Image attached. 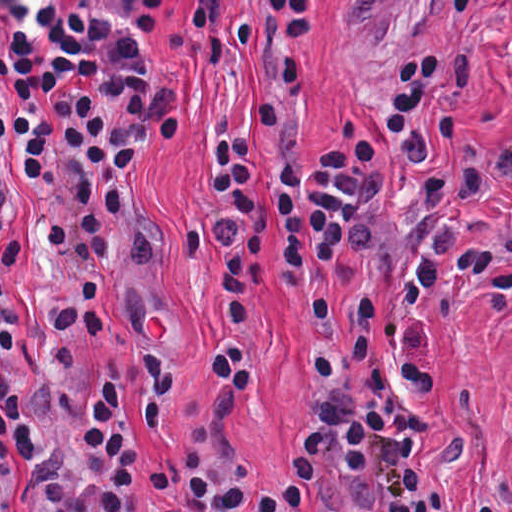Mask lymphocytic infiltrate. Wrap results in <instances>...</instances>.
<instances>
[{"label":"lymphocytic infiltrate","instance_id":"lymphocytic-infiltrate-1","mask_svg":"<svg viewBox=\"0 0 512 512\" xmlns=\"http://www.w3.org/2000/svg\"><path fill=\"white\" fill-rule=\"evenodd\" d=\"M318 316L320 419L282 466H262L232 435V411L259 381L251 336L215 351L223 392L159 488L188 512H512L467 505L429 454L437 369L425 313L512 306V204L303 297ZM149 428L180 406V363L145 367ZM124 379L0 431V512L20 452L44 512H140L143 467Z\"/></svg>","mask_w":512,"mask_h":512}]
</instances>
